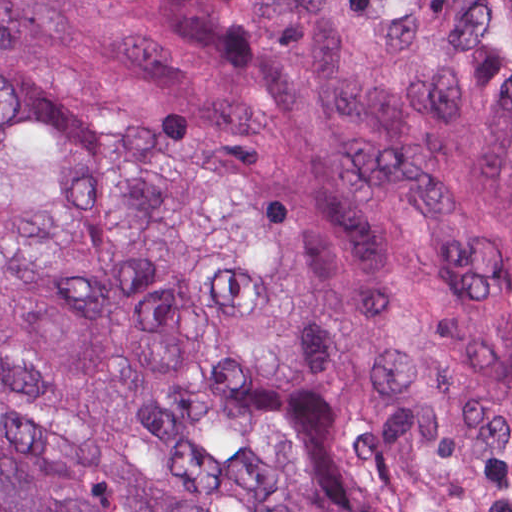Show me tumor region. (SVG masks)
I'll list each match as a JSON object with an SVG mask.
<instances>
[{
    "instance_id": "1",
    "label": "tumor region",
    "mask_w": 512,
    "mask_h": 512,
    "mask_svg": "<svg viewBox=\"0 0 512 512\" xmlns=\"http://www.w3.org/2000/svg\"><path fill=\"white\" fill-rule=\"evenodd\" d=\"M0 512H512V0H0Z\"/></svg>"
}]
</instances>
